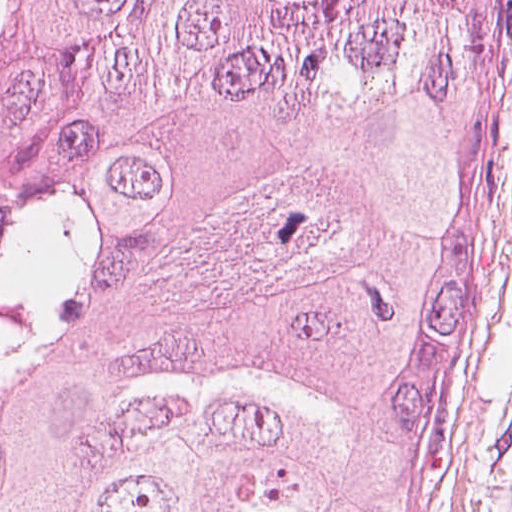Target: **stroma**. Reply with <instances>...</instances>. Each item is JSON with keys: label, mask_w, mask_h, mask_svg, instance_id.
I'll list each match as a JSON object with an SVG mask.
<instances>
[{"label": "stroma", "mask_w": 512, "mask_h": 512, "mask_svg": "<svg viewBox=\"0 0 512 512\" xmlns=\"http://www.w3.org/2000/svg\"><path fill=\"white\" fill-rule=\"evenodd\" d=\"M492 179L444 421L413 512H500L512 454V0L493 32Z\"/></svg>", "instance_id": "obj_1"}]
</instances>
